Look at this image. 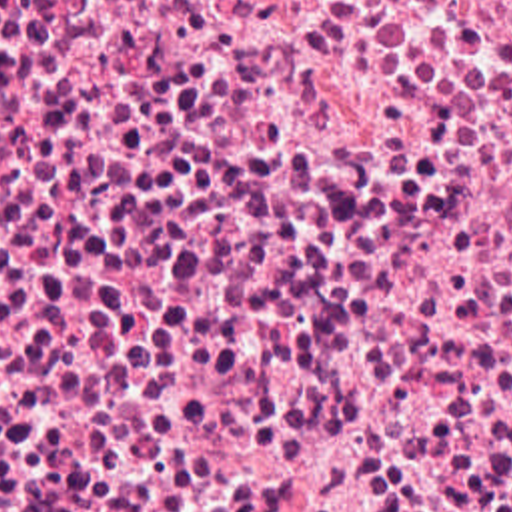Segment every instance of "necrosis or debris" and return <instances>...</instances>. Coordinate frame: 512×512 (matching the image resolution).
Wrapping results in <instances>:
<instances>
[{
  "label": "necrosis or debris",
  "mask_w": 512,
  "mask_h": 512,
  "mask_svg": "<svg viewBox=\"0 0 512 512\" xmlns=\"http://www.w3.org/2000/svg\"><path fill=\"white\" fill-rule=\"evenodd\" d=\"M0 428H512V0H0Z\"/></svg>",
  "instance_id": "1"
}]
</instances>
